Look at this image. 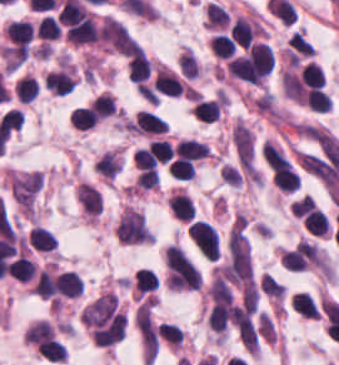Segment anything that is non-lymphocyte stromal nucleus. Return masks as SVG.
I'll list each match as a JSON object with an SVG mask.
<instances>
[{"mask_svg": "<svg viewBox=\"0 0 339 365\" xmlns=\"http://www.w3.org/2000/svg\"><path fill=\"white\" fill-rule=\"evenodd\" d=\"M42 186L39 171L14 172L8 176L10 197L25 215H33Z\"/></svg>", "mask_w": 339, "mask_h": 365, "instance_id": "obj_1", "label": "non-lymphocyte stromal nucleus"}, {"mask_svg": "<svg viewBox=\"0 0 339 365\" xmlns=\"http://www.w3.org/2000/svg\"><path fill=\"white\" fill-rule=\"evenodd\" d=\"M118 164H119V154L117 156H115L112 160H110L108 163H106L104 166H102L96 172L102 178L108 179V178L118 174Z\"/></svg>", "mask_w": 339, "mask_h": 365, "instance_id": "obj_6", "label": "non-lymphocyte stromal nucleus"}, {"mask_svg": "<svg viewBox=\"0 0 339 365\" xmlns=\"http://www.w3.org/2000/svg\"><path fill=\"white\" fill-rule=\"evenodd\" d=\"M114 234L117 241L126 244L152 242L142 213L132 208H124L114 227Z\"/></svg>", "mask_w": 339, "mask_h": 365, "instance_id": "obj_2", "label": "non-lymphocyte stromal nucleus"}, {"mask_svg": "<svg viewBox=\"0 0 339 365\" xmlns=\"http://www.w3.org/2000/svg\"><path fill=\"white\" fill-rule=\"evenodd\" d=\"M99 38L118 53L129 55L139 48L126 26L112 15L103 16L99 28Z\"/></svg>", "mask_w": 339, "mask_h": 365, "instance_id": "obj_3", "label": "non-lymphocyte stromal nucleus"}, {"mask_svg": "<svg viewBox=\"0 0 339 365\" xmlns=\"http://www.w3.org/2000/svg\"><path fill=\"white\" fill-rule=\"evenodd\" d=\"M232 139L240 165L253 170L254 139L251 128L238 121L232 131Z\"/></svg>", "mask_w": 339, "mask_h": 365, "instance_id": "obj_4", "label": "non-lymphocyte stromal nucleus"}, {"mask_svg": "<svg viewBox=\"0 0 339 365\" xmlns=\"http://www.w3.org/2000/svg\"><path fill=\"white\" fill-rule=\"evenodd\" d=\"M76 198L87 214H100L102 212V197L89 184L81 183L76 189Z\"/></svg>", "mask_w": 339, "mask_h": 365, "instance_id": "obj_5", "label": "non-lymphocyte stromal nucleus"}]
</instances>
